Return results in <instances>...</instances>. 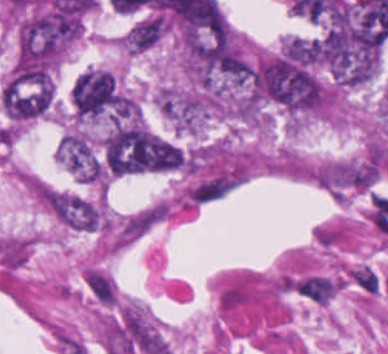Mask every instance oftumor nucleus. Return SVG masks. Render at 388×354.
<instances>
[{
	"label": "tumor nucleus",
	"mask_w": 388,
	"mask_h": 354,
	"mask_svg": "<svg viewBox=\"0 0 388 354\" xmlns=\"http://www.w3.org/2000/svg\"><path fill=\"white\" fill-rule=\"evenodd\" d=\"M57 152L62 164L80 180L102 181L104 172L97 151L86 133L67 131L57 145Z\"/></svg>",
	"instance_id": "obj_3"
},
{
	"label": "tumor nucleus",
	"mask_w": 388,
	"mask_h": 354,
	"mask_svg": "<svg viewBox=\"0 0 388 354\" xmlns=\"http://www.w3.org/2000/svg\"><path fill=\"white\" fill-rule=\"evenodd\" d=\"M54 97L49 70H15L1 92L3 114L15 124L48 114Z\"/></svg>",
	"instance_id": "obj_1"
},
{
	"label": "tumor nucleus",
	"mask_w": 388,
	"mask_h": 354,
	"mask_svg": "<svg viewBox=\"0 0 388 354\" xmlns=\"http://www.w3.org/2000/svg\"><path fill=\"white\" fill-rule=\"evenodd\" d=\"M85 281L96 299L105 305H112L116 298V287L101 269L87 268Z\"/></svg>",
	"instance_id": "obj_5"
},
{
	"label": "tumor nucleus",
	"mask_w": 388,
	"mask_h": 354,
	"mask_svg": "<svg viewBox=\"0 0 388 354\" xmlns=\"http://www.w3.org/2000/svg\"><path fill=\"white\" fill-rule=\"evenodd\" d=\"M45 203L52 215L66 226L102 229V210L82 195L46 186Z\"/></svg>",
	"instance_id": "obj_2"
},
{
	"label": "tumor nucleus",
	"mask_w": 388,
	"mask_h": 354,
	"mask_svg": "<svg viewBox=\"0 0 388 354\" xmlns=\"http://www.w3.org/2000/svg\"><path fill=\"white\" fill-rule=\"evenodd\" d=\"M166 31L162 15L151 14L129 28L124 34L126 50L143 51L157 42Z\"/></svg>",
	"instance_id": "obj_4"
}]
</instances>
